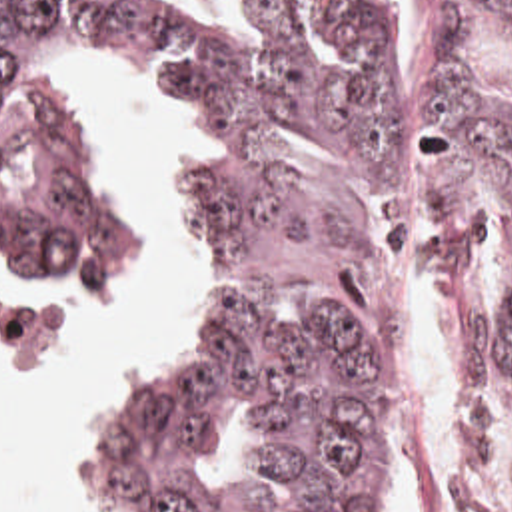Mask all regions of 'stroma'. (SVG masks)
<instances>
[{
  "label": "stroma",
  "mask_w": 512,
  "mask_h": 512,
  "mask_svg": "<svg viewBox=\"0 0 512 512\" xmlns=\"http://www.w3.org/2000/svg\"><path fill=\"white\" fill-rule=\"evenodd\" d=\"M418 1L410 0L406 23L400 35L398 51H396V63H394V75H392V193L396 187L398 177L404 181V185L410 189V55L414 45V13L418 7ZM52 65L66 77V81L72 85L76 95L86 107V119H88V135L92 143L94 157L98 161V167L108 183V187L124 201L130 217H132V249L128 263L120 267L116 273L104 279H92V281H0V359L6 361H42L56 353L64 339V331L60 321L54 317L50 309L36 303L34 299L50 297V295H76V293H88L98 291L120 277L128 275L144 257L148 239H150V209L142 193L136 189V185L128 179L124 173L122 161L118 153L112 149L108 141L106 127L102 123V117L96 109V103L92 99V93L86 83L80 81L76 69L82 67H134L140 69L144 79L158 91V95L164 99L170 119L176 127V175L168 183L164 191V207H162V239L164 249L168 253V259L172 263L174 271V289L164 305V311L152 331L150 343L146 351L126 369L122 381H126L130 375H134L140 367H144L148 361H152L160 349L174 339L178 333L184 331L188 315H190V255L186 249V243L178 229L172 223V199L178 179L184 175L188 161L194 151V125L190 111L182 99V95L174 89V85L160 77L158 73L144 69L140 65L112 59V57H64L58 61H52ZM120 381V383H122ZM112 385L100 405V409L106 405L110 395L120 385ZM98 409V413H100ZM96 413V415H98ZM94 415V417H96ZM92 417V421H94ZM90 421V423H92ZM88 423V425H90ZM86 427H82L76 451L70 459L68 477H66V512H72V465L80 453L82 439L86 433ZM466 435V367H464V355L460 345V455ZM0 512H8V495L4 491V463L0 457Z\"/></svg>",
  "instance_id": "35a3bbf8"
}]
</instances>
